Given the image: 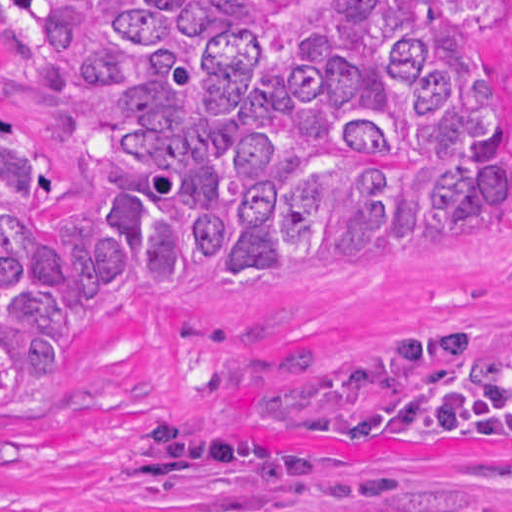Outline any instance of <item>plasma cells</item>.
<instances>
[{
    "label": "plasma cells",
    "instance_id": "9512152a",
    "mask_svg": "<svg viewBox=\"0 0 512 512\" xmlns=\"http://www.w3.org/2000/svg\"><path fill=\"white\" fill-rule=\"evenodd\" d=\"M351 504H310L302 512H512L508 504H418L377 495L331 498Z\"/></svg>",
    "mask_w": 512,
    "mask_h": 512
}]
</instances>
